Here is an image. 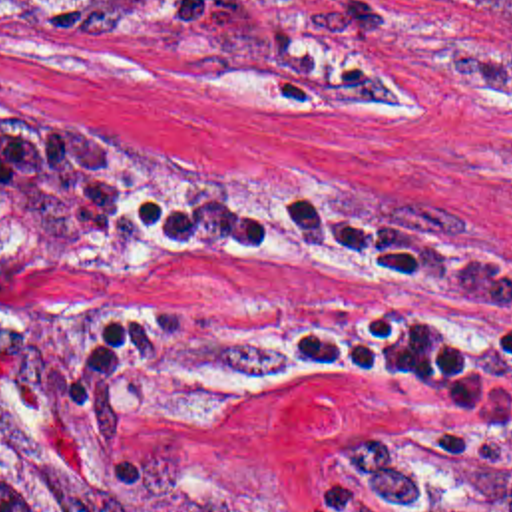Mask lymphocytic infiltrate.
<instances>
[{"mask_svg":"<svg viewBox=\"0 0 512 512\" xmlns=\"http://www.w3.org/2000/svg\"><path fill=\"white\" fill-rule=\"evenodd\" d=\"M121 238H234L290 264L427 268L401 288L262 300L254 334L346 381L449 399L415 429L328 461L310 512H512V268L342 188L300 180H157L101 160L77 192Z\"/></svg>","mask_w":512,"mask_h":512,"instance_id":"1","label":"lymphocytic infiltrate"}]
</instances>
